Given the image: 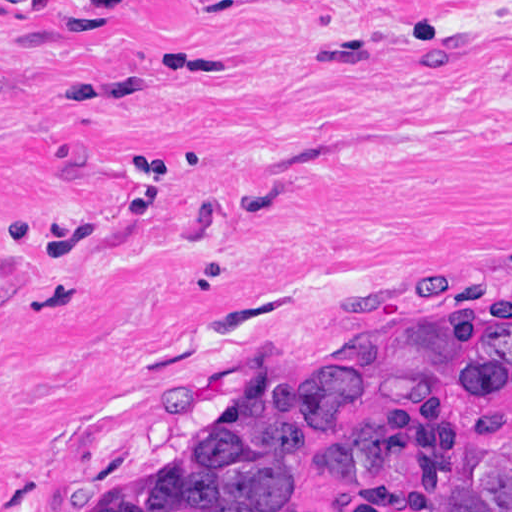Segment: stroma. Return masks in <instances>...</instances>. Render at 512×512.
<instances>
[{
	"mask_svg": "<svg viewBox=\"0 0 512 512\" xmlns=\"http://www.w3.org/2000/svg\"><path fill=\"white\" fill-rule=\"evenodd\" d=\"M511 312L512 0H0V512L342 326Z\"/></svg>",
	"mask_w": 512,
	"mask_h": 512,
	"instance_id": "stroma-1",
	"label": "stroma"
}]
</instances>
